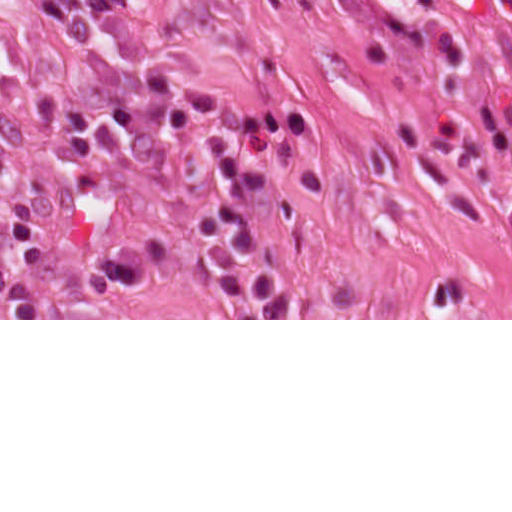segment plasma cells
I'll return each instance as SVG.
<instances>
[{
  "mask_svg": "<svg viewBox=\"0 0 512 512\" xmlns=\"http://www.w3.org/2000/svg\"><path fill=\"white\" fill-rule=\"evenodd\" d=\"M163 124L173 142L187 141L208 126L215 129L209 164L221 198L196 226L193 246L209 280L228 299L233 319H289V291L246 256L258 242L246 204L271 184L270 176L253 161L265 149L288 146L297 161L303 156L309 144L306 114L293 106L242 109L208 90L188 88L166 107ZM148 271L146 250L128 243L90 271L82 286L95 298H116L138 288Z\"/></svg>",
  "mask_w": 512,
  "mask_h": 512,
  "instance_id": "9512152a",
  "label": "plasma cells"
}]
</instances>
